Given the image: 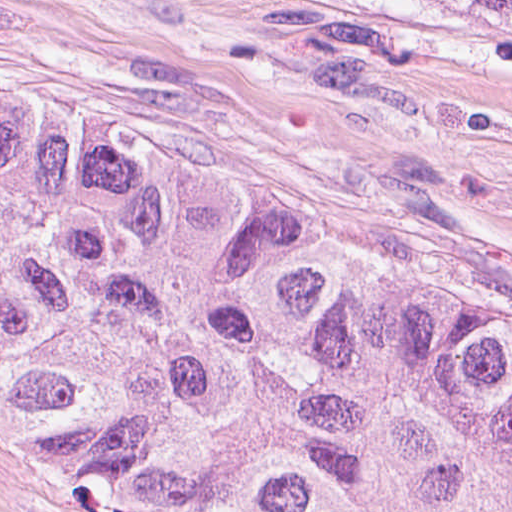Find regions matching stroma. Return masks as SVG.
<instances>
[{
  "instance_id": "35a3bbf8",
  "label": "stroma",
  "mask_w": 512,
  "mask_h": 512,
  "mask_svg": "<svg viewBox=\"0 0 512 512\" xmlns=\"http://www.w3.org/2000/svg\"><path fill=\"white\" fill-rule=\"evenodd\" d=\"M0 96L215 153L512 278V29L451 0H0ZM0 512H185L28 458Z\"/></svg>"
}]
</instances>
